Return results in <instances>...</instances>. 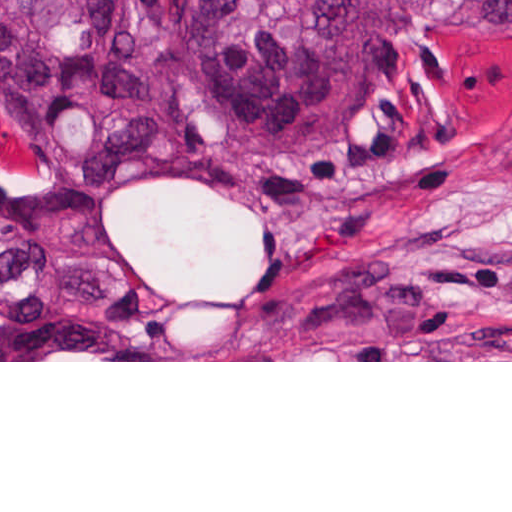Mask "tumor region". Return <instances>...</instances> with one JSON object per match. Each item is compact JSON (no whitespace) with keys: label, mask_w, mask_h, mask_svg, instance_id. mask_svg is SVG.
Here are the masks:
<instances>
[{"label":"tumor region","mask_w":512,"mask_h":512,"mask_svg":"<svg viewBox=\"0 0 512 512\" xmlns=\"http://www.w3.org/2000/svg\"><path fill=\"white\" fill-rule=\"evenodd\" d=\"M430 0H0V360H119L148 288L90 207L141 176L253 203L250 183L171 146L142 74L182 77L277 152L330 142L375 101ZM473 36H512V0H461Z\"/></svg>","instance_id":"1"}]
</instances>
